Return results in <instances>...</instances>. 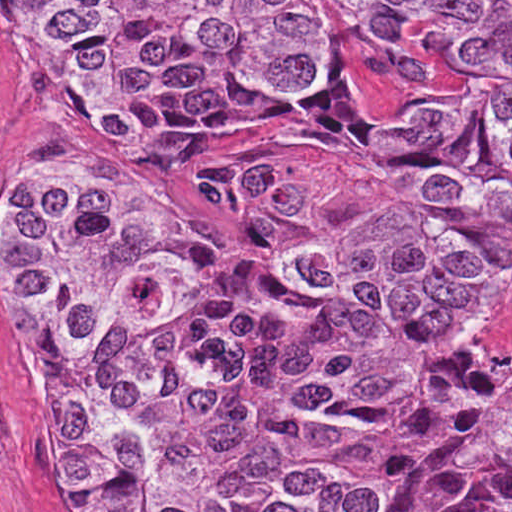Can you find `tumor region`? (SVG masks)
Here are the masks:
<instances>
[{"mask_svg":"<svg viewBox=\"0 0 512 512\" xmlns=\"http://www.w3.org/2000/svg\"><path fill=\"white\" fill-rule=\"evenodd\" d=\"M84 112L205 138L311 82L306 1H23ZM512 50V1H371ZM459 215L394 214L289 258L323 196L283 166L202 171L244 245L141 181L46 163L0 203V296L54 512H512V375L432 362L512 286V62L407 122L342 61L281 113Z\"/></svg>","mask_w":512,"mask_h":512,"instance_id":"e687c5a6","label":"tumor region"}]
</instances>
